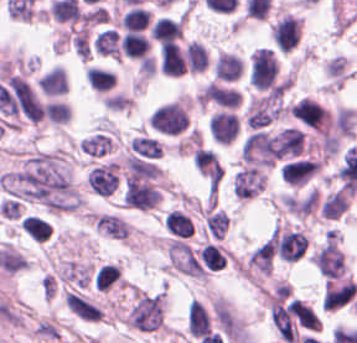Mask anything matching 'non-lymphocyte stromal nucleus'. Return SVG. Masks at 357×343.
Returning <instances> with one entry per match:
<instances>
[{
    "instance_id": "obj_1",
    "label": "non-lymphocyte stromal nucleus",
    "mask_w": 357,
    "mask_h": 343,
    "mask_svg": "<svg viewBox=\"0 0 357 343\" xmlns=\"http://www.w3.org/2000/svg\"><path fill=\"white\" fill-rule=\"evenodd\" d=\"M88 187L100 199L111 197L121 189V164L107 157L94 163L88 172Z\"/></svg>"
},
{
    "instance_id": "obj_2",
    "label": "non-lymphocyte stromal nucleus",
    "mask_w": 357,
    "mask_h": 343,
    "mask_svg": "<svg viewBox=\"0 0 357 343\" xmlns=\"http://www.w3.org/2000/svg\"><path fill=\"white\" fill-rule=\"evenodd\" d=\"M283 92L278 91L252 99L246 115L251 127H265L286 112Z\"/></svg>"
},
{
    "instance_id": "obj_3",
    "label": "non-lymphocyte stromal nucleus",
    "mask_w": 357,
    "mask_h": 343,
    "mask_svg": "<svg viewBox=\"0 0 357 343\" xmlns=\"http://www.w3.org/2000/svg\"><path fill=\"white\" fill-rule=\"evenodd\" d=\"M167 256L171 267L190 277H205V270L191 248L180 240L169 241Z\"/></svg>"
},
{
    "instance_id": "obj_4",
    "label": "non-lymphocyte stromal nucleus",
    "mask_w": 357,
    "mask_h": 343,
    "mask_svg": "<svg viewBox=\"0 0 357 343\" xmlns=\"http://www.w3.org/2000/svg\"><path fill=\"white\" fill-rule=\"evenodd\" d=\"M89 223L97 235L107 240H127L129 225L119 214L112 211H99L89 215Z\"/></svg>"
},
{
    "instance_id": "obj_5",
    "label": "non-lymphocyte stromal nucleus",
    "mask_w": 357,
    "mask_h": 343,
    "mask_svg": "<svg viewBox=\"0 0 357 343\" xmlns=\"http://www.w3.org/2000/svg\"><path fill=\"white\" fill-rule=\"evenodd\" d=\"M267 183L266 174L260 168H246L234 174V194L250 199L260 194Z\"/></svg>"
},
{
    "instance_id": "obj_6",
    "label": "non-lymphocyte stromal nucleus",
    "mask_w": 357,
    "mask_h": 343,
    "mask_svg": "<svg viewBox=\"0 0 357 343\" xmlns=\"http://www.w3.org/2000/svg\"><path fill=\"white\" fill-rule=\"evenodd\" d=\"M67 307L86 322H100L102 311L100 307L74 292H66Z\"/></svg>"
},
{
    "instance_id": "obj_7",
    "label": "non-lymphocyte stromal nucleus",
    "mask_w": 357,
    "mask_h": 343,
    "mask_svg": "<svg viewBox=\"0 0 357 343\" xmlns=\"http://www.w3.org/2000/svg\"><path fill=\"white\" fill-rule=\"evenodd\" d=\"M133 153L158 159L163 153V141L151 133L138 132L130 138Z\"/></svg>"
},
{
    "instance_id": "obj_8",
    "label": "non-lymphocyte stromal nucleus",
    "mask_w": 357,
    "mask_h": 343,
    "mask_svg": "<svg viewBox=\"0 0 357 343\" xmlns=\"http://www.w3.org/2000/svg\"><path fill=\"white\" fill-rule=\"evenodd\" d=\"M93 46L97 54L121 59L118 34L113 28H106L96 34Z\"/></svg>"
},
{
    "instance_id": "obj_9",
    "label": "non-lymphocyte stromal nucleus",
    "mask_w": 357,
    "mask_h": 343,
    "mask_svg": "<svg viewBox=\"0 0 357 343\" xmlns=\"http://www.w3.org/2000/svg\"><path fill=\"white\" fill-rule=\"evenodd\" d=\"M207 227L213 238L223 239L229 229V217L221 210H209Z\"/></svg>"
}]
</instances>
